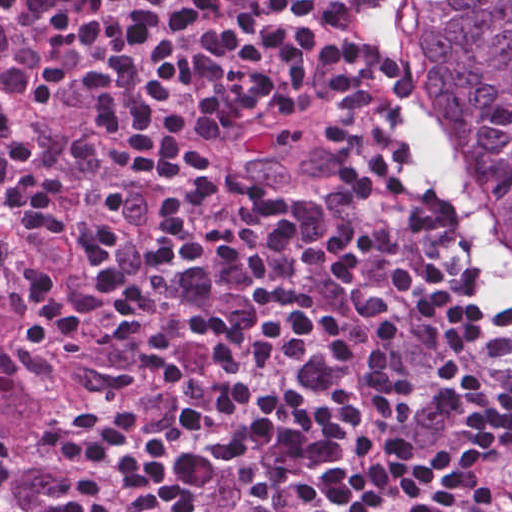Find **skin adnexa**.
I'll return each mask as SVG.
<instances>
[{
  "label": "skin adnexa",
  "mask_w": 512,
  "mask_h": 512,
  "mask_svg": "<svg viewBox=\"0 0 512 512\" xmlns=\"http://www.w3.org/2000/svg\"><path fill=\"white\" fill-rule=\"evenodd\" d=\"M416 119L512 288V0H386Z\"/></svg>",
  "instance_id": "obj_1"
}]
</instances>
